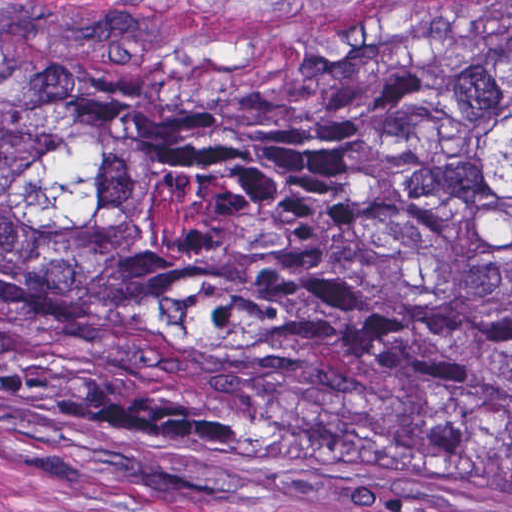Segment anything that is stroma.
<instances>
[{
	"label": "stroma",
	"instance_id": "1",
	"mask_svg": "<svg viewBox=\"0 0 512 512\" xmlns=\"http://www.w3.org/2000/svg\"><path fill=\"white\" fill-rule=\"evenodd\" d=\"M0 33L149 67L332 66L512 34V0H0ZM0 512H512V465L191 458L0 388Z\"/></svg>",
	"mask_w": 512,
	"mask_h": 512
}]
</instances>
